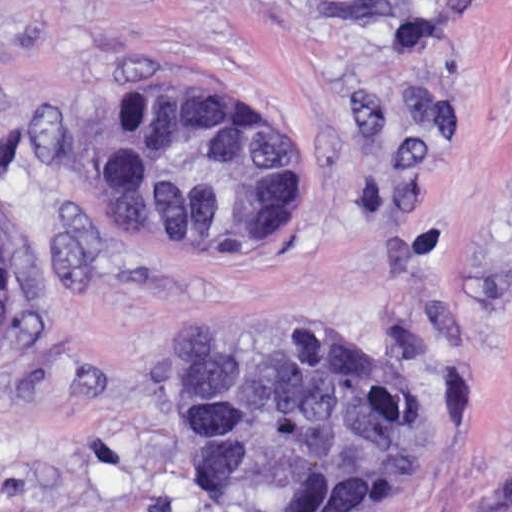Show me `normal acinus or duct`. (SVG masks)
I'll return each instance as SVG.
<instances>
[{
    "mask_svg": "<svg viewBox=\"0 0 512 512\" xmlns=\"http://www.w3.org/2000/svg\"><path fill=\"white\" fill-rule=\"evenodd\" d=\"M88 179L136 244L226 236L311 185V157L265 106L198 90H132L95 124ZM13 255L0 237V342ZM388 373L290 339L189 331L176 350L174 429L211 482L298 507H342L387 474L397 439Z\"/></svg>",
    "mask_w": 512,
    "mask_h": 512,
    "instance_id": "1",
    "label": "normal acinus or duct"
}]
</instances>
